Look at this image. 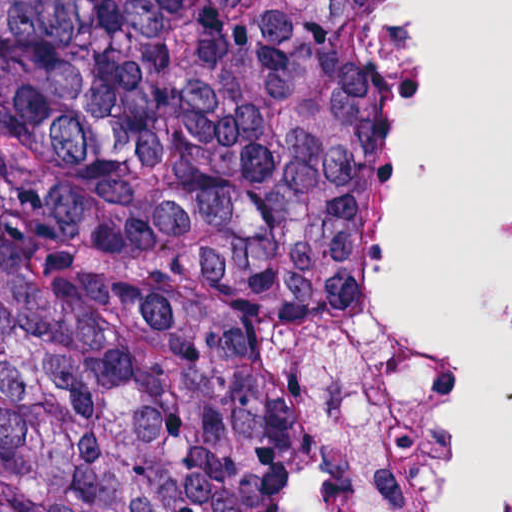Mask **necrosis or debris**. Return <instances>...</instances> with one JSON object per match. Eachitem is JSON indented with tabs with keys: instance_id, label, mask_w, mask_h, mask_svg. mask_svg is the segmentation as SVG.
<instances>
[{
	"instance_id": "necrosis-or-debris-1",
	"label": "necrosis or debris",
	"mask_w": 512,
	"mask_h": 512,
	"mask_svg": "<svg viewBox=\"0 0 512 512\" xmlns=\"http://www.w3.org/2000/svg\"><path fill=\"white\" fill-rule=\"evenodd\" d=\"M386 80L393 120V190L408 110V59L403 0H386ZM386 303V249L350 322L331 380L268 485L242 512H300L346 417L352 386ZM497 506L474 512H491ZM335 512H465L418 461L363 462L340 484Z\"/></svg>"
}]
</instances>
